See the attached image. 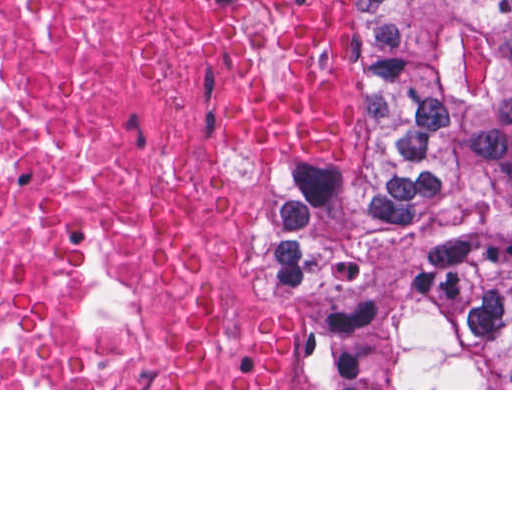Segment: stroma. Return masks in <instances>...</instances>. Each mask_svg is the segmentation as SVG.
<instances>
[{"mask_svg":"<svg viewBox=\"0 0 512 512\" xmlns=\"http://www.w3.org/2000/svg\"><path fill=\"white\" fill-rule=\"evenodd\" d=\"M351 41L354 83L363 101V128L347 156L335 160H295L231 138L217 121V101L238 54L268 32L276 20V0H261L257 37L222 66L200 93V134L217 150L236 157L252 179L256 204L276 185H345L370 179L380 154V118L369 93V22L365 0H311ZM237 272L255 278L257 292L294 344L292 388H156L166 354L172 316L199 286ZM314 365V347L302 322V306L288 297L264 269L253 242V216L205 248L181 273L160 315V345L150 388H0V390H512V389H302Z\"/></svg>","mask_w":512,"mask_h":512,"instance_id":"stroma-1","label":"stroma"}]
</instances>
